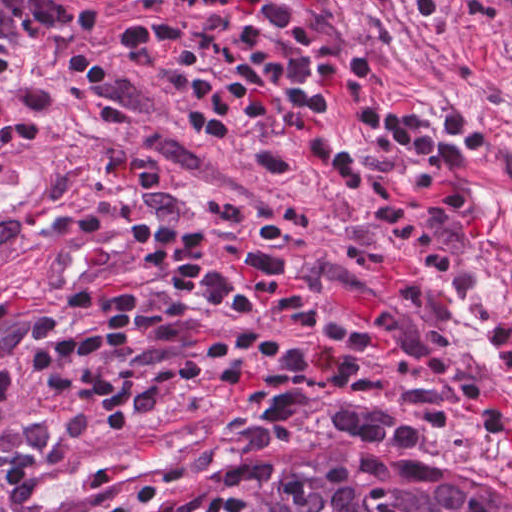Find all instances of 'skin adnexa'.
Returning <instances> with one entry per match:
<instances>
[{"mask_svg": "<svg viewBox=\"0 0 512 512\" xmlns=\"http://www.w3.org/2000/svg\"><path fill=\"white\" fill-rule=\"evenodd\" d=\"M204 512H512V481L455 458H365L253 484Z\"/></svg>", "mask_w": 512, "mask_h": 512, "instance_id": "obj_1", "label": "skin adnexa"}]
</instances>
